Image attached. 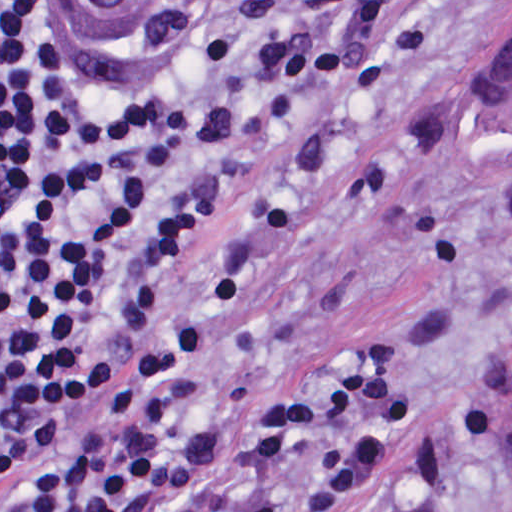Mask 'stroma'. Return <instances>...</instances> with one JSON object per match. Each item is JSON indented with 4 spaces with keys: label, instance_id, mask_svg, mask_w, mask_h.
Returning a JSON list of instances; mask_svg holds the SVG:
<instances>
[{
    "label": "stroma",
    "instance_id": "35a3bbf8",
    "mask_svg": "<svg viewBox=\"0 0 512 512\" xmlns=\"http://www.w3.org/2000/svg\"><path fill=\"white\" fill-rule=\"evenodd\" d=\"M291 91L379 194L316 238L269 302L264 379L305 378L363 334L467 325V408L397 482L350 512H512V184L479 161L460 102L512 39V0H161ZM382 193H390L392 197Z\"/></svg>",
    "mask_w": 512,
    "mask_h": 512
}]
</instances>
